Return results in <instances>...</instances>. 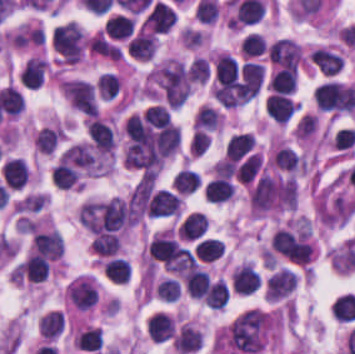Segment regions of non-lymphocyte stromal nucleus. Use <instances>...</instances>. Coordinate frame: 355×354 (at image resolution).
<instances>
[{"label": "non-lymphocyte stromal nucleus", "instance_id": "dd21d789", "mask_svg": "<svg viewBox=\"0 0 355 354\" xmlns=\"http://www.w3.org/2000/svg\"><path fill=\"white\" fill-rule=\"evenodd\" d=\"M267 326L268 315L262 310L253 307L242 310L227 330V341L239 351L256 353L262 349Z\"/></svg>", "mask_w": 355, "mask_h": 354}, {"label": "non-lymphocyte stromal nucleus", "instance_id": "a72fc3eb", "mask_svg": "<svg viewBox=\"0 0 355 354\" xmlns=\"http://www.w3.org/2000/svg\"><path fill=\"white\" fill-rule=\"evenodd\" d=\"M63 330V312L51 310L42 316L41 333L55 338Z\"/></svg>", "mask_w": 355, "mask_h": 354}]
</instances>
